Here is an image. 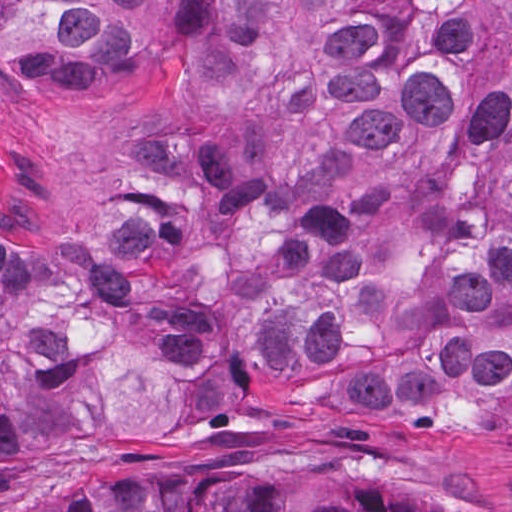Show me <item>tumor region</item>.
Returning a JSON list of instances; mask_svg holds the SVG:
<instances>
[{
    "label": "tumor region",
    "instance_id": "tumor-region-1",
    "mask_svg": "<svg viewBox=\"0 0 512 512\" xmlns=\"http://www.w3.org/2000/svg\"><path fill=\"white\" fill-rule=\"evenodd\" d=\"M142 73L73 281L215 396L473 413L512 388V0H0L43 90ZM0 252V466L60 454L56 334ZM68 512H424L381 489L196 473Z\"/></svg>",
    "mask_w": 512,
    "mask_h": 512
}]
</instances>
